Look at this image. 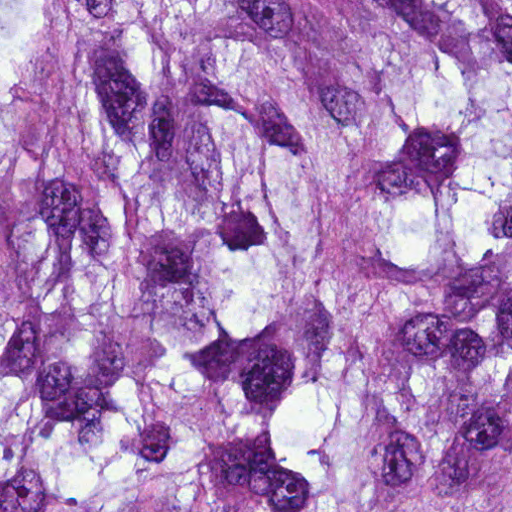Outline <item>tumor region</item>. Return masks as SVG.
I'll use <instances>...</instances> for the list:
<instances>
[{"label":"tumor region","mask_w":512,"mask_h":512,"mask_svg":"<svg viewBox=\"0 0 512 512\" xmlns=\"http://www.w3.org/2000/svg\"><path fill=\"white\" fill-rule=\"evenodd\" d=\"M0 512H512V0H0Z\"/></svg>","instance_id":"1"}]
</instances>
